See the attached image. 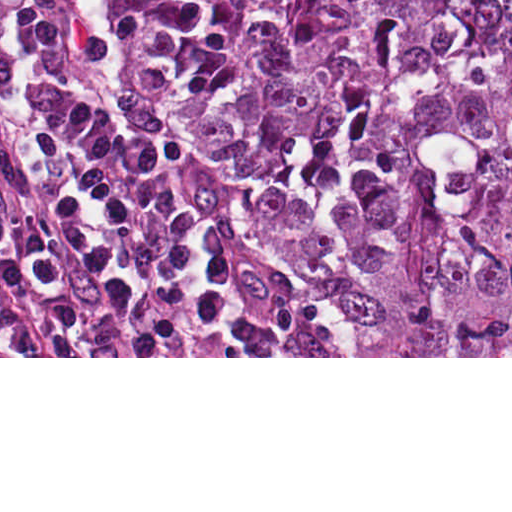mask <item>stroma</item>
<instances>
[{"mask_svg":"<svg viewBox=\"0 0 512 512\" xmlns=\"http://www.w3.org/2000/svg\"><path fill=\"white\" fill-rule=\"evenodd\" d=\"M90 19V70L94 95L100 107L117 116L139 134L163 144L175 155L202 166L226 182L243 218L267 256L279 264L299 291L327 316L343 356H0V358H512V356H348L345 320L333 296L295 264L258 222L242 196V177L230 166L215 163L186 136L165 121L142 116L124 106L112 89V72L118 57V29L110 0H87ZM242 196V197H241ZM241 197V198H240ZM240 198V199H239Z\"/></svg>","mask_w":512,"mask_h":512,"instance_id":"stroma-1","label":"stroma"}]
</instances>
